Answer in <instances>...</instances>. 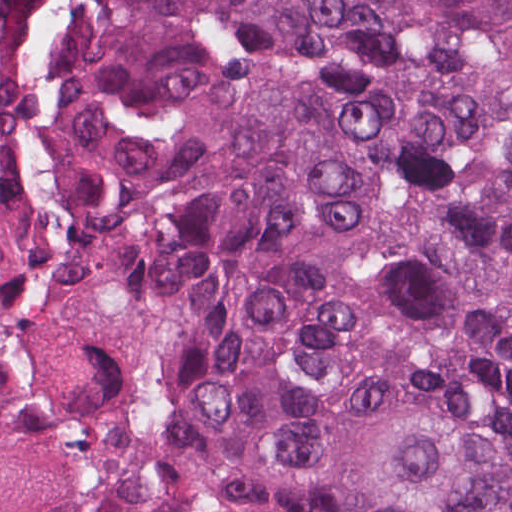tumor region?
Listing matches in <instances>:
<instances>
[{
  "label": "tumor region",
  "instance_id": "1",
  "mask_svg": "<svg viewBox=\"0 0 512 512\" xmlns=\"http://www.w3.org/2000/svg\"><path fill=\"white\" fill-rule=\"evenodd\" d=\"M0 512H512V0H0Z\"/></svg>",
  "mask_w": 512,
  "mask_h": 512
}]
</instances>
